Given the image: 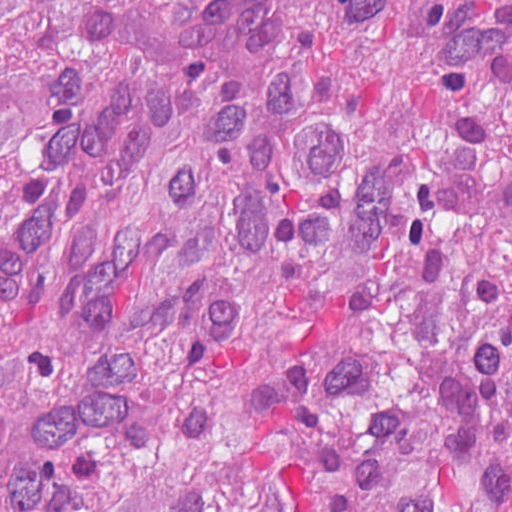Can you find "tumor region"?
I'll return each instance as SVG.
<instances>
[{
    "mask_svg": "<svg viewBox=\"0 0 512 512\" xmlns=\"http://www.w3.org/2000/svg\"><path fill=\"white\" fill-rule=\"evenodd\" d=\"M0 512H512V0H0Z\"/></svg>",
    "mask_w": 512,
    "mask_h": 512,
    "instance_id": "e687c5a6",
    "label": "tumor region"
}]
</instances>
